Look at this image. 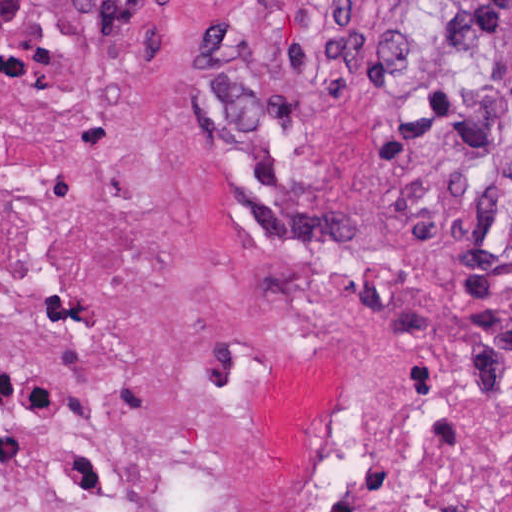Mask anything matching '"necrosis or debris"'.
Masks as SVG:
<instances>
[{
	"mask_svg": "<svg viewBox=\"0 0 512 512\" xmlns=\"http://www.w3.org/2000/svg\"><path fill=\"white\" fill-rule=\"evenodd\" d=\"M348 38L145 152L0 122V512H512V186Z\"/></svg>",
	"mask_w": 512,
	"mask_h": 512,
	"instance_id": "4bbe7bcc",
	"label": "necrosis or debris"
}]
</instances>
